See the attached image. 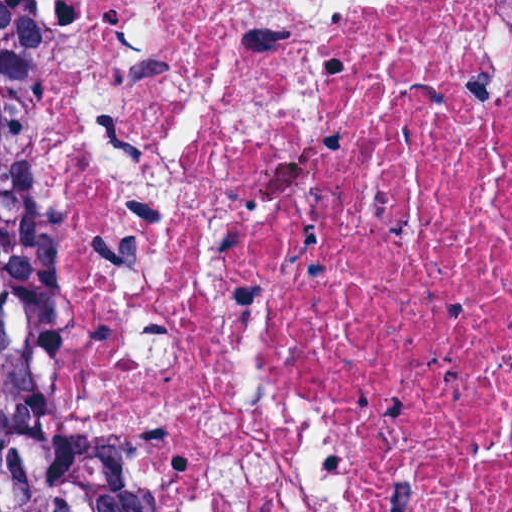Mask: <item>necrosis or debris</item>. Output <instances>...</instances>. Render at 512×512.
Segmentation results:
<instances>
[{"instance_id": "4bbe7bcc", "label": "necrosis or debris", "mask_w": 512, "mask_h": 512, "mask_svg": "<svg viewBox=\"0 0 512 512\" xmlns=\"http://www.w3.org/2000/svg\"><path fill=\"white\" fill-rule=\"evenodd\" d=\"M0 296L130 512H512V0H0Z\"/></svg>"}]
</instances>
